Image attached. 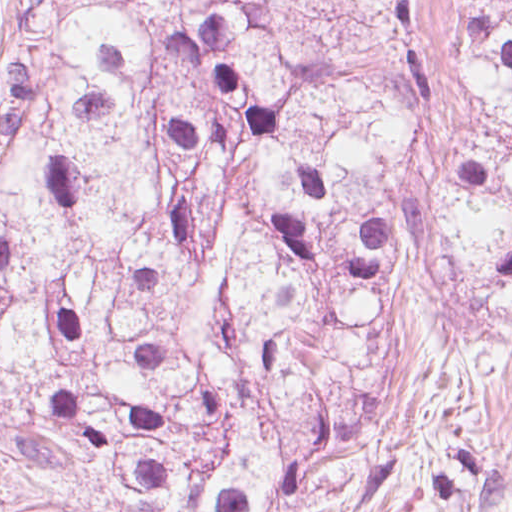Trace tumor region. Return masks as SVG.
<instances>
[{
	"label": "tumor region",
	"instance_id": "obj_1",
	"mask_svg": "<svg viewBox=\"0 0 512 512\" xmlns=\"http://www.w3.org/2000/svg\"><path fill=\"white\" fill-rule=\"evenodd\" d=\"M482 119L269 44L245 0H26L0 92V512H451L468 417L402 386L435 224L512 334V0H449Z\"/></svg>",
	"mask_w": 512,
	"mask_h": 512
}]
</instances>
